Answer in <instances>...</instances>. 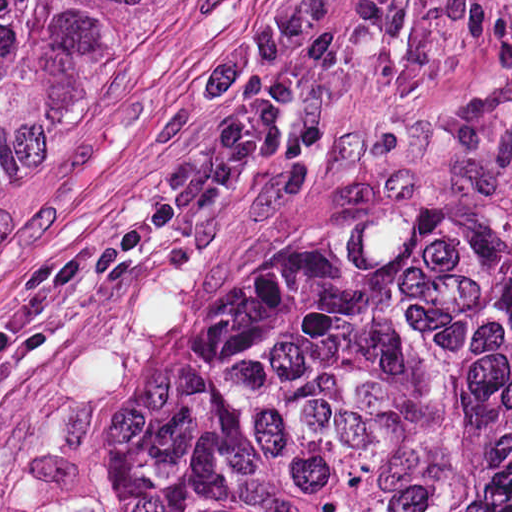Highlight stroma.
I'll list each match as a JSON object with an SVG mask.
<instances>
[{"label":"stroma","mask_w":512,"mask_h":512,"mask_svg":"<svg viewBox=\"0 0 512 512\" xmlns=\"http://www.w3.org/2000/svg\"><path fill=\"white\" fill-rule=\"evenodd\" d=\"M317 2L155 0L0 140V512H59L106 407L144 399L226 264L470 204L512 240V0H438L284 106L175 253H115L203 140L189 78Z\"/></svg>","instance_id":"35a3bbf8"}]
</instances>
